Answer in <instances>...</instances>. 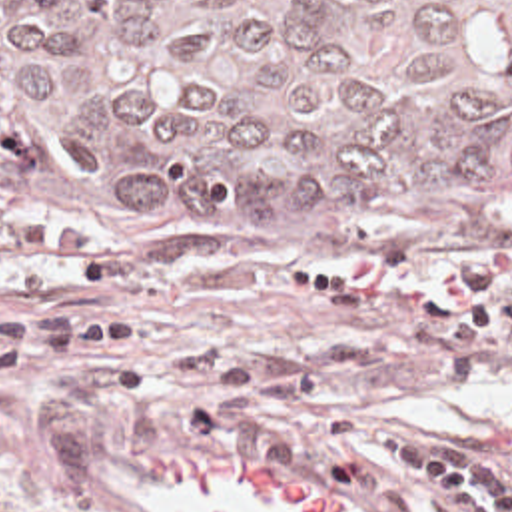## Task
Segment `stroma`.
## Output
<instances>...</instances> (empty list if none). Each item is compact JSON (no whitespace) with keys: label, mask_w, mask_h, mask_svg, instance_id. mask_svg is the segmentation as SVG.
I'll list each match as a JSON object with an SVG mask.
<instances>
[{"label":"stroma","mask_w":512,"mask_h":512,"mask_svg":"<svg viewBox=\"0 0 512 512\" xmlns=\"http://www.w3.org/2000/svg\"><path fill=\"white\" fill-rule=\"evenodd\" d=\"M498 210V250H418L402 242L326 238L263 220L163 208H85L0 184V240L17 218H51L107 252L125 278L67 296L5 294L11 310L113 312L143 326V352L125 360L55 362L0 380V512H175L149 484L153 462L233 456L291 474L346 500L352 512H458L436 490L352 464L326 432L293 464L201 446L191 414L209 380L161 370L179 350H219L239 370L297 386L318 410L372 422L466 452L512 482V456H480L478 426L512 416V348L486 370H448L424 322L372 318L340 304L279 294L283 270L410 294H454L468 264L512 290V204ZM243 512H263L223 500Z\"/></svg>","instance_id":"stroma-1"}]
</instances>
